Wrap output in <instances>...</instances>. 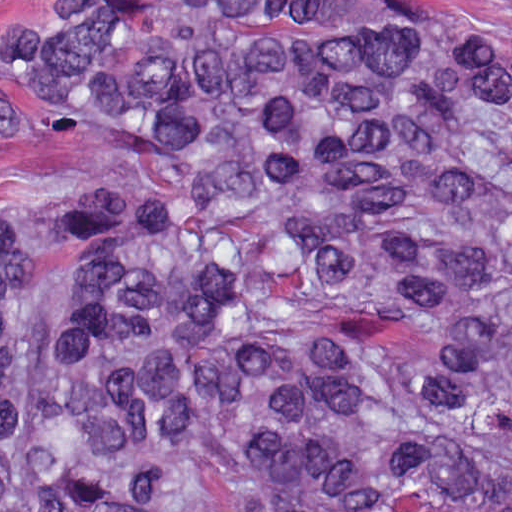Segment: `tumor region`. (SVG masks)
<instances>
[{"label": "tumor region", "mask_w": 512, "mask_h": 512, "mask_svg": "<svg viewBox=\"0 0 512 512\" xmlns=\"http://www.w3.org/2000/svg\"><path fill=\"white\" fill-rule=\"evenodd\" d=\"M0 46L86 153L0 183V500L512 512V11L22 0Z\"/></svg>", "instance_id": "e687c5a6"}]
</instances>
